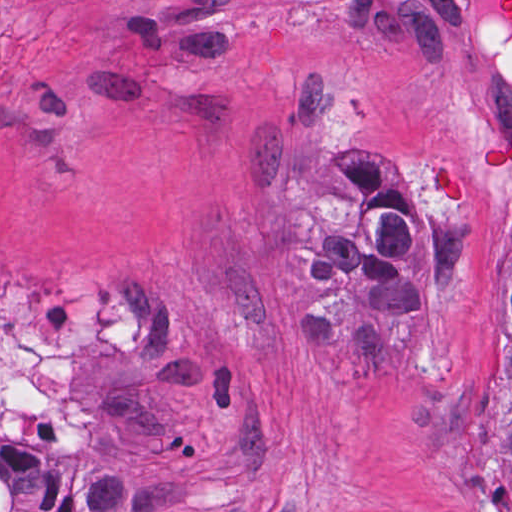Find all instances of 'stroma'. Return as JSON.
Instances as JSON below:
<instances>
[{
    "label": "stroma",
    "mask_w": 512,
    "mask_h": 512,
    "mask_svg": "<svg viewBox=\"0 0 512 512\" xmlns=\"http://www.w3.org/2000/svg\"><path fill=\"white\" fill-rule=\"evenodd\" d=\"M496 1L0 0V290L102 314L77 481L35 512H512V173L476 188L512 141ZM356 142L471 227L465 300L417 311L384 389L300 344L298 182Z\"/></svg>",
    "instance_id": "35a3bbf8"
}]
</instances>
